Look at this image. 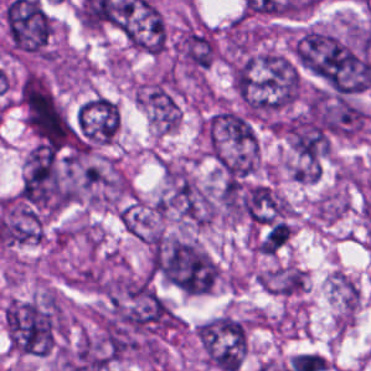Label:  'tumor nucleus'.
<instances>
[{"mask_svg": "<svg viewBox=\"0 0 371 371\" xmlns=\"http://www.w3.org/2000/svg\"><path fill=\"white\" fill-rule=\"evenodd\" d=\"M153 276L181 293L211 291L218 274L215 262L187 241L155 239L151 247Z\"/></svg>", "mask_w": 371, "mask_h": 371, "instance_id": "8643909e", "label": "tumor nucleus"}, {"mask_svg": "<svg viewBox=\"0 0 371 371\" xmlns=\"http://www.w3.org/2000/svg\"><path fill=\"white\" fill-rule=\"evenodd\" d=\"M296 60L333 93L348 95L367 87L371 59L321 30H308L296 44Z\"/></svg>", "mask_w": 371, "mask_h": 371, "instance_id": "2f306a5c", "label": "tumor nucleus"}, {"mask_svg": "<svg viewBox=\"0 0 371 371\" xmlns=\"http://www.w3.org/2000/svg\"><path fill=\"white\" fill-rule=\"evenodd\" d=\"M201 345L211 363L223 371H237L246 350V331L231 317H217L204 323Z\"/></svg>", "mask_w": 371, "mask_h": 371, "instance_id": "5ab6c2c4", "label": "tumor nucleus"}, {"mask_svg": "<svg viewBox=\"0 0 371 371\" xmlns=\"http://www.w3.org/2000/svg\"><path fill=\"white\" fill-rule=\"evenodd\" d=\"M206 130L212 145H247L253 140L251 125L239 113L230 111L211 117Z\"/></svg>", "mask_w": 371, "mask_h": 371, "instance_id": "2cbd58db", "label": "tumor nucleus"}, {"mask_svg": "<svg viewBox=\"0 0 371 371\" xmlns=\"http://www.w3.org/2000/svg\"><path fill=\"white\" fill-rule=\"evenodd\" d=\"M148 103L163 127H174L177 112L174 100L165 85H158L150 92Z\"/></svg>", "mask_w": 371, "mask_h": 371, "instance_id": "2083b535", "label": "tumor nucleus"}, {"mask_svg": "<svg viewBox=\"0 0 371 371\" xmlns=\"http://www.w3.org/2000/svg\"><path fill=\"white\" fill-rule=\"evenodd\" d=\"M291 136L293 149L301 157L318 163L328 143L324 130L303 117H296L291 122Z\"/></svg>", "mask_w": 371, "mask_h": 371, "instance_id": "3d1891a8", "label": "tumor nucleus"}, {"mask_svg": "<svg viewBox=\"0 0 371 371\" xmlns=\"http://www.w3.org/2000/svg\"><path fill=\"white\" fill-rule=\"evenodd\" d=\"M184 53L192 66L207 67L212 62L210 38L203 33L190 31L184 41Z\"/></svg>", "mask_w": 371, "mask_h": 371, "instance_id": "8087334f", "label": "tumor nucleus"}]
</instances>
